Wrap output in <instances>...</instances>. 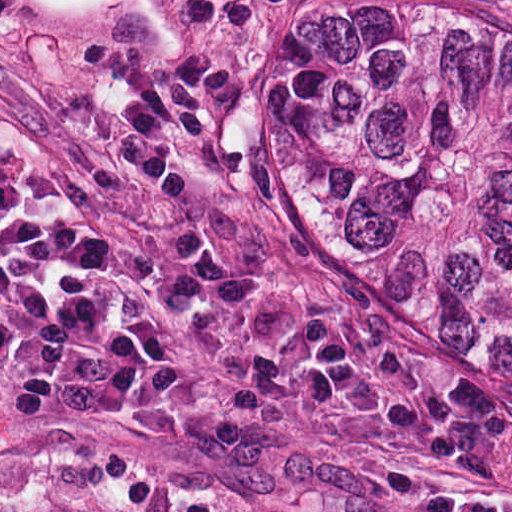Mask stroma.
<instances>
[{
  "label": "stroma",
  "instance_id": "1",
  "mask_svg": "<svg viewBox=\"0 0 512 512\" xmlns=\"http://www.w3.org/2000/svg\"><path fill=\"white\" fill-rule=\"evenodd\" d=\"M108 294L176 348L181 390L0 412V512H512V424Z\"/></svg>",
  "mask_w": 512,
  "mask_h": 512
}]
</instances>
